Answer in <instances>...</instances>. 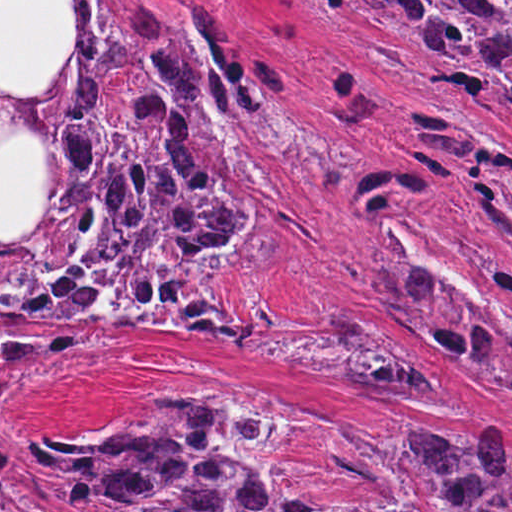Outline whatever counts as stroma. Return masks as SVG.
Masks as SVG:
<instances>
[{
    "label": "stroma",
    "instance_id": "35a3bbf8",
    "mask_svg": "<svg viewBox=\"0 0 512 512\" xmlns=\"http://www.w3.org/2000/svg\"><path fill=\"white\" fill-rule=\"evenodd\" d=\"M68 1H94L90 23L106 36L149 17L211 39L258 93L295 97V123L311 139L290 152L258 130L280 165L276 201L262 209L286 253L233 270L225 301L276 314L331 304L382 346L411 348L442 395L350 385L148 327L38 324L35 332L91 337L53 362L0 368V455L143 405L209 395L301 426L345 458L434 429H462L470 445L503 429L512 450V401L383 314V240H396L418 270L512 325V295L490 270L493 260L512 268V247L474 209L512 200V101L485 74L478 91L446 76L408 81L332 2L512 0H0V90L32 93L50 80L67 49Z\"/></svg>",
    "mask_w": 512,
    "mask_h": 512
}]
</instances>
